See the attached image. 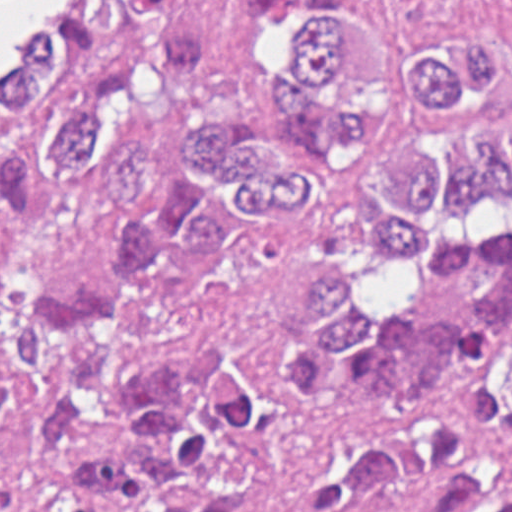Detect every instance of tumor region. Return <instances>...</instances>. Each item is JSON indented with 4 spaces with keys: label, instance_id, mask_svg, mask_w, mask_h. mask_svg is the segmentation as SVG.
<instances>
[{
    "label": "tumor region",
    "instance_id": "1",
    "mask_svg": "<svg viewBox=\"0 0 512 512\" xmlns=\"http://www.w3.org/2000/svg\"><path fill=\"white\" fill-rule=\"evenodd\" d=\"M108 1L0 133V512H512V72L478 36ZM58 188L98 274L10 278Z\"/></svg>",
    "mask_w": 512,
    "mask_h": 512
}]
</instances>
